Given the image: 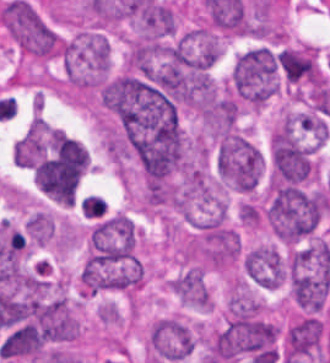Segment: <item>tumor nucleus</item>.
Here are the masks:
<instances>
[{
    "label": "tumor nucleus",
    "instance_id": "1",
    "mask_svg": "<svg viewBox=\"0 0 330 363\" xmlns=\"http://www.w3.org/2000/svg\"><path fill=\"white\" fill-rule=\"evenodd\" d=\"M59 52L70 83H103L109 69L110 44L100 30H87L63 40Z\"/></svg>",
    "mask_w": 330,
    "mask_h": 363
},
{
    "label": "tumor nucleus",
    "instance_id": "2",
    "mask_svg": "<svg viewBox=\"0 0 330 363\" xmlns=\"http://www.w3.org/2000/svg\"><path fill=\"white\" fill-rule=\"evenodd\" d=\"M264 168L258 146L240 131L228 130L217 143L216 170L232 188L250 191L259 181Z\"/></svg>",
    "mask_w": 330,
    "mask_h": 363
},
{
    "label": "tumor nucleus",
    "instance_id": "3",
    "mask_svg": "<svg viewBox=\"0 0 330 363\" xmlns=\"http://www.w3.org/2000/svg\"><path fill=\"white\" fill-rule=\"evenodd\" d=\"M0 20L24 54L51 55L59 50L52 29L25 0H12L1 7Z\"/></svg>",
    "mask_w": 330,
    "mask_h": 363
},
{
    "label": "tumor nucleus",
    "instance_id": "4",
    "mask_svg": "<svg viewBox=\"0 0 330 363\" xmlns=\"http://www.w3.org/2000/svg\"><path fill=\"white\" fill-rule=\"evenodd\" d=\"M147 340L157 361L172 363L189 355L194 345V331L184 320L167 315L152 323Z\"/></svg>",
    "mask_w": 330,
    "mask_h": 363
},
{
    "label": "tumor nucleus",
    "instance_id": "5",
    "mask_svg": "<svg viewBox=\"0 0 330 363\" xmlns=\"http://www.w3.org/2000/svg\"><path fill=\"white\" fill-rule=\"evenodd\" d=\"M242 268L257 286L275 288L286 279L283 256L275 245L257 244L245 250Z\"/></svg>",
    "mask_w": 330,
    "mask_h": 363
},
{
    "label": "tumor nucleus",
    "instance_id": "6",
    "mask_svg": "<svg viewBox=\"0 0 330 363\" xmlns=\"http://www.w3.org/2000/svg\"><path fill=\"white\" fill-rule=\"evenodd\" d=\"M172 293L183 302L210 307V292L197 265L185 267L169 278Z\"/></svg>",
    "mask_w": 330,
    "mask_h": 363
}]
</instances>
